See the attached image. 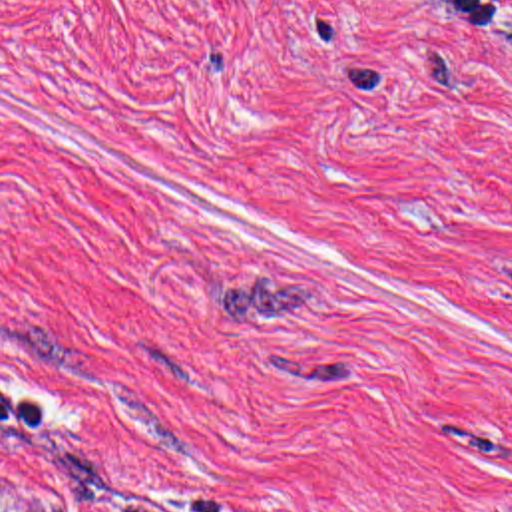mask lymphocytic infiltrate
<instances>
[{"label": "lymphocytic infiltrate", "mask_w": 512, "mask_h": 512, "mask_svg": "<svg viewBox=\"0 0 512 512\" xmlns=\"http://www.w3.org/2000/svg\"><path fill=\"white\" fill-rule=\"evenodd\" d=\"M38 429V393L10 389L0 399V477H4L22 439ZM111 512H237L215 481L203 473H187L165 495L135 499Z\"/></svg>", "instance_id": "obj_1"}]
</instances>
